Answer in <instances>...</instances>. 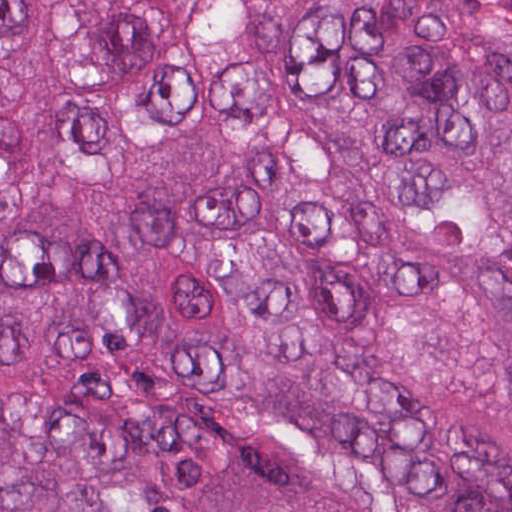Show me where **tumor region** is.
<instances>
[{
	"label": "tumor region",
	"mask_w": 512,
	"mask_h": 512,
	"mask_svg": "<svg viewBox=\"0 0 512 512\" xmlns=\"http://www.w3.org/2000/svg\"><path fill=\"white\" fill-rule=\"evenodd\" d=\"M0 512H512V0H0Z\"/></svg>",
	"instance_id": "1"
}]
</instances>
